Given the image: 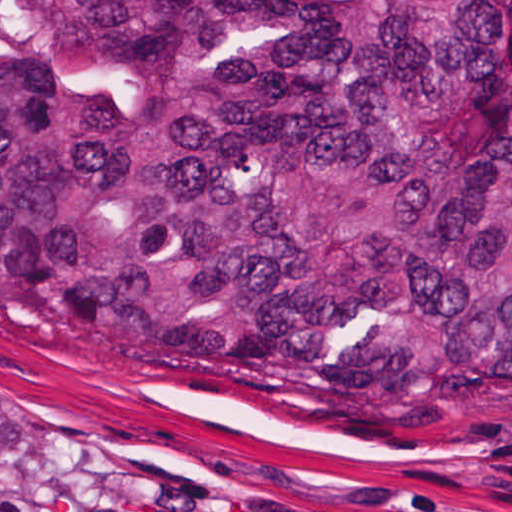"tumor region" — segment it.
Returning <instances> with one entry per match:
<instances>
[{"label": "tumor region", "instance_id": "e687c5a6", "mask_svg": "<svg viewBox=\"0 0 512 512\" xmlns=\"http://www.w3.org/2000/svg\"><path fill=\"white\" fill-rule=\"evenodd\" d=\"M0 337L259 411L512 394V0H0Z\"/></svg>", "mask_w": 512, "mask_h": 512}]
</instances>
